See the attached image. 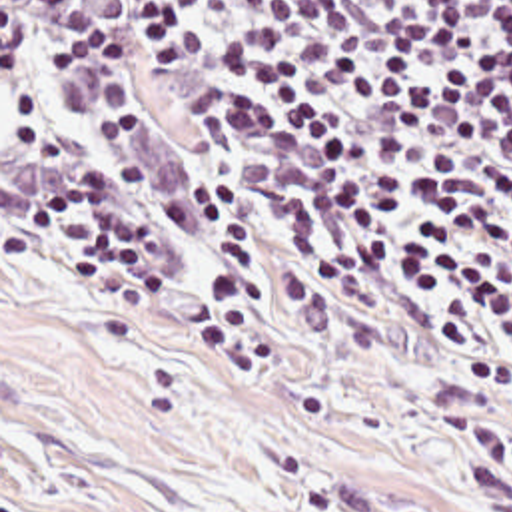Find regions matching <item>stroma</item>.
I'll return each instance as SVG.
<instances>
[{
  "label": "stroma",
  "mask_w": 512,
  "mask_h": 512,
  "mask_svg": "<svg viewBox=\"0 0 512 512\" xmlns=\"http://www.w3.org/2000/svg\"><path fill=\"white\" fill-rule=\"evenodd\" d=\"M82 512H512V398L273 303L182 330L56 271Z\"/></svg>",
  "instance_id": "stroma-1"
}]
</instances>
